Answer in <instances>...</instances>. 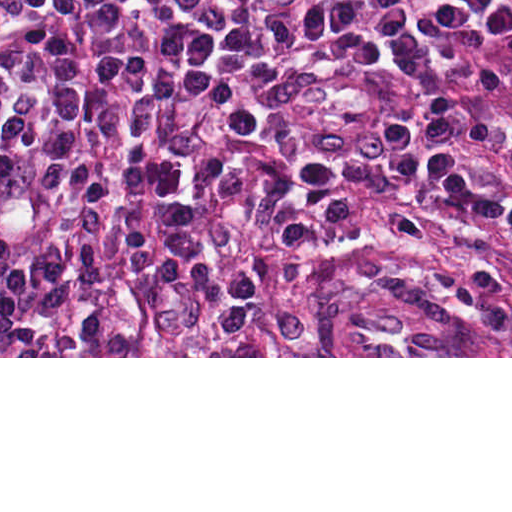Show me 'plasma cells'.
Instances as JSON below:
<instances>
[{
    "label": "plasma cells",
    "mask_w": 512,
    "mask_h": 512,
    "mask_svg": "<svg viewBox=\"0 0 512 512\" xmlns=\"http://www.w3.org/2000/svg\"><path fill=\"white\" fill-rule=\"evenodd\" d=\"M512 233V0H0V356H257L286 212Z\"/></svg>",
    "instance_id": "obj_1"
}]
</instances>
